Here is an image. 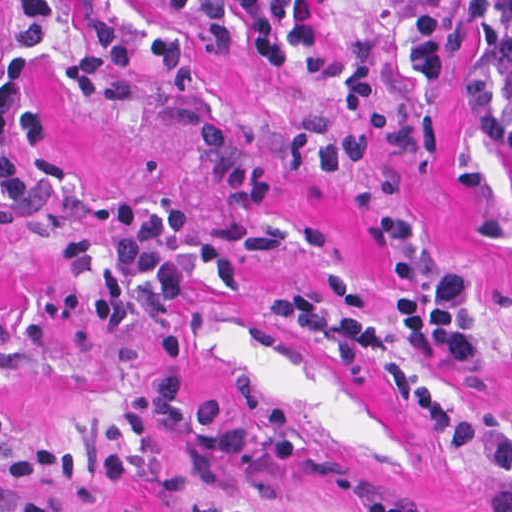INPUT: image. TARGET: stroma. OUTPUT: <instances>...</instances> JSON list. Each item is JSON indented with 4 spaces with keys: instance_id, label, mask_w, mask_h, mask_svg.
<instances>
[{
    "instance_id": "35a3bbf8",
    "label": "stroma",
    "mask_w": 512,
    "mask_h": 512,
    "mask_svg": "<svg viewBox=\"0 0 512 512\" xmlns=\"http://www.w3.org/2000/svg\"><path fill=\"white\" fill-rule=\"evenodd\" d=\"M53 1L60 32L38 82L52 109L46 151L74 193L64 216L0 223V320L12 325L0 355L7 456L45 439L70 447L83 475L38 480L58 512H365L363 493L408 512H484L483 494L509 480L450 452L426 416L407 406L390 370L411 369L463 420L512 434V113L475 111L447 91L407 0H296L313 10L322 34L300 60L348 59L374 72L388 109L409 121L418 145L342 173L279 171L266 207L239 210L222 200L195 130L217 124L276 143L292 119L332 113L333 92L235 56L215 60L194 90L170 88L138 65L136 92L94 102L68 81L82 55L80 15L138 35L192 22L167 15L164 0ZM112 199L187 208L181 241L225 245L242 288L227 292L183 263L189 290L181 300L168 304L142 288L124 327L102 334L91 309L100 277L75 272L66 248L78 240L116 253L118 236L92 220ZM387 213L410 220L429 266L466 271L477 362L424 356L406 343L347 370L266 310L273 292L327 302L334 270L356 276L366 312L391 310L394 264L372 237ZM161 376L178 378L185 413L214 398L223 423L259 429L256 448L214 469L184 433L162 425L170 465L101 486L106 451L143 447L123 428L122 409ZM22 504L19 486L0 478V512Z\"/></svg>"
}]
</instances>
